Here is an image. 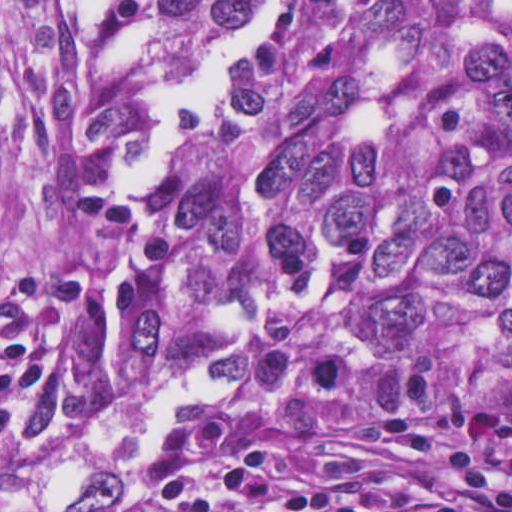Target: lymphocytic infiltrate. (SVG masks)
<instances>
[{
	"label": "lymphocytic infiltrate",
	"instance_id": "obj_1",
	"mask_svg": "<svg viewBox=\"0 0 512 512\" xmlns=\"http://www.w3.org/2000/svg\"><path fill=\"white\" fill-rule=\"evenodd\" d=\"M294 392L205 415L140 452L133 477L151 496L137 512H444L421 495L369 491L343 480L342 459L312 436L265 444L248 466L223 474L236 438L283 410L315 411L347 381L334 353L296 360ZM386 439L472 500L512 512V411L405 412L383 419Z\"/></svg>",
	"mask_w": 512,
	"mask_h": 512
}]
</instances>
